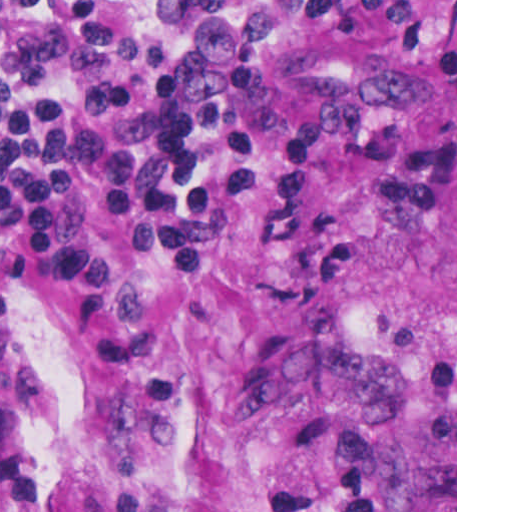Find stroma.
<instances>
[{
    "label": "stroma",
    "instance_id": "obj_1",
    "mask_svg": "<svg viewBox=\"0 0 512 512\" xmlns=\"http://www.w3.org/2000/svg\"><path fill=\"white\" fill-rule=\"evenodd\" d=\"M257 60L291 124L357 105L360 129L313 145L276 230L277 143L243 191L188 130L219 206L203 273L97 212L153 359L74 358L50 286L0 301V512H457V0L455 68L321 32Z\"/></svg>",
    "mask_w": 512,
    "mask_h": 512
}]
</instances>
